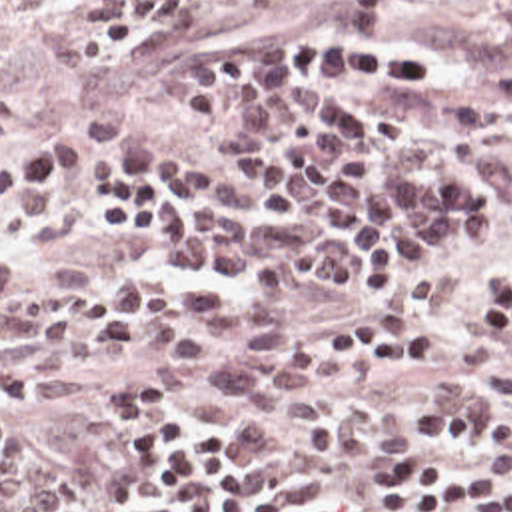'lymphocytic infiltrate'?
<instances>
[{
	"label": "lymphocytic infiltrate",
	"instance_id": "f902f5d3",
	"mask_svg": "<svg viewBox=\"0 0 512 512\" xmlns=\"http://www.w3.org/2000/svg\"><path fill=\"white\" fill-rule=\"evenodd\" d=\"M184 18L188 0H94L78 41L80 67L112 75ZM481 297L493 343H512V279L487 283ZM431 349L433 333L412 323H376L324 341L326 357L340 367H386ZM20 371L22 353L0 345L4 395L34 403ZM108 399L126 411L118 475L142 493L144 512H340L330 497L242 453L216 423L182 417L144 377H118ZM483 441L491 459H453L412 441L392 447L374 463V487L400 512H512V439Z\"/></svg>",
	"mask_w": 512,
	"mask_h": 512
}]
</instances>
